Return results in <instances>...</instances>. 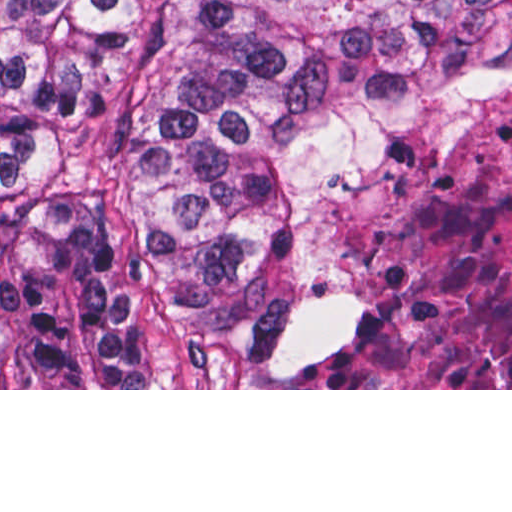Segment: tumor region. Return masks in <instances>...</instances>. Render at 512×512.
<instances>
[{
    "instance_id": "e687c5a6",
    "label": "tumor region",
    "mask_w": 512,
    "mask_h": 512,
    "mask_svg": "<svg viewBox=\"0 0 512 512\" xmlns=\"http://www.w3.org/2000/svg\"><path fill=\"white\" fill-rule=\"evenodd\" d=\"M512 0H0V389L282 370L357 97L479 109Z\"/></svg>"
}]
</instances>
